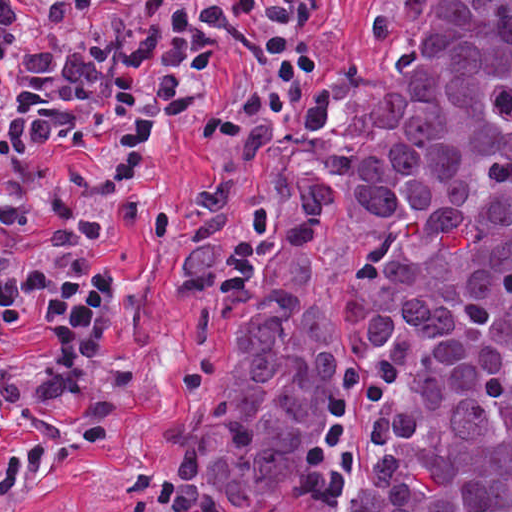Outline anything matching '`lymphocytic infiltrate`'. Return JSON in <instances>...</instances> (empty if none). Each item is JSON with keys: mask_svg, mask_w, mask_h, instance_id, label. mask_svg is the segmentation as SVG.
<instances>
[{"mask_svg": "<svg viewBox=\"0 0 512 512\" xmlns=\"http://www.w3.org/2000/svg\"><path fill=\"white\" fill-rule=\"evenodd\" d=\"M313 0H0V512L119 429L143 357L107 334L162 144L228 82L193 157L233 161L320 66ZM130 512H171L150 494Z\"/></svg>", "mask_w": 512, "mask_h": 512, "instance_id": "1", "label": "lymphocytic infiltrate"}]
</instances>
